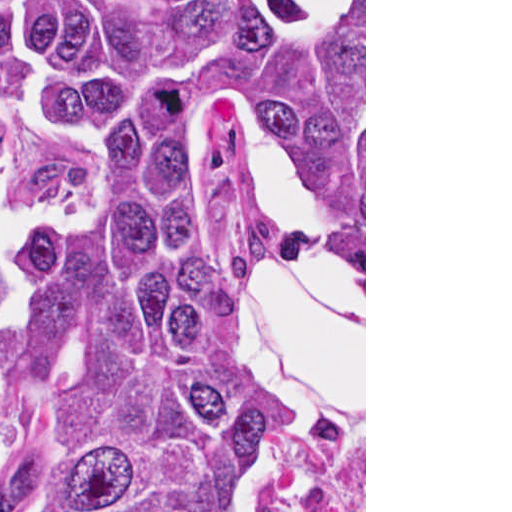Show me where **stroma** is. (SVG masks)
Masks as SVG:
<instances>
[{"label":"stroma","instance_id":"1","mask_svg":"<svg viewBox=\"0 0 512 512\" xmlns=\"http://www.w3.org/2000/svg\"><path fill=\"white\" fill-rule=\"evenodd\" d=\"M0 1H364V249H365V398L361 399L354 410L356 413L365 408V512H366V0H0ZM270 244L259 246L242 254L235 269L263 258ZM339 423L329 432L338 429ZM326 433H299L295 432L287 439L320 436ZM355 508L344 510L352 512Z\"/></svg>","mask_w":512,"mask_h":512}]
</instances>
